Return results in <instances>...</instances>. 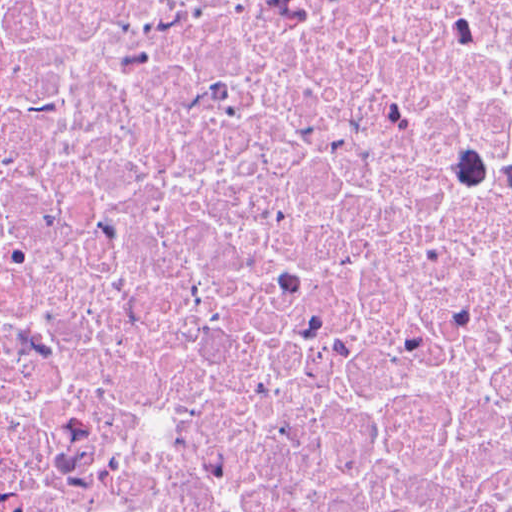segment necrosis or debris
<instances>
[{
    "mask_svg": "<svg viewBox=\"0 0 512 512\" xmlns=\"http://www.w3.org/2000/svg\"><path fill=\"white\" fill-rule=\"evenodd\" d=\"M0 512H512V0H0Z\"/></svg>",
    "mask_w": 512,
    "mask_h": 512,
    "instance_id": "necrosis-or-debris-1",
    "label": "necrosis or debris"
}]
</instances>
